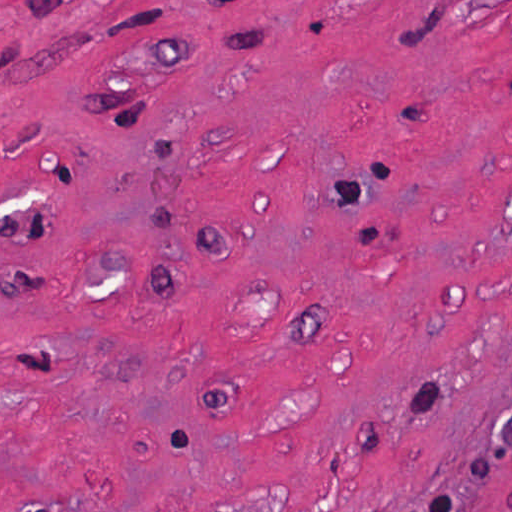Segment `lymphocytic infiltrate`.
Wrapping results in <instances>:
<instances>
[{"mask_svg":"<svg viewBox=\"0 0 512 512\" xmlns=\"http://www.w3.org/2000/svg\"><path fill=\"white\" fill-rule=\"evenodd\" d=\"M402 512H459V507L450 494L437 493Z\"/></svg>","mask_w":512,"mask_h":512,"instance_id":"lymphocytic-infiltrate-1","label":"lymphocytic infiltrate"}]
</instances>
